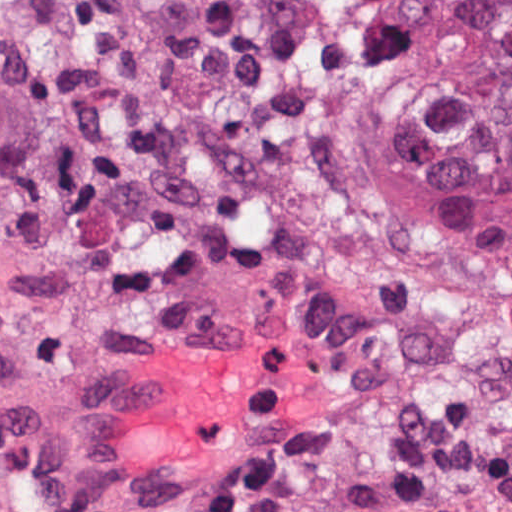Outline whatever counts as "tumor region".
I'll return each instance as SVG.
<instances>
[{"label":"tumor region","instance_id":"obj_1","mask_svg":"<svg viewBox=\"0 0 512 512\" xmlns=\"http://www.w3.org/2000/svg\"><path fill=\"white\" fill-rule=\"evenodd\" d=\"M393 79L419 183L512 258V0H426Z\"/></svg>","mask_w":512,"mask_h":512}]
</instances>
